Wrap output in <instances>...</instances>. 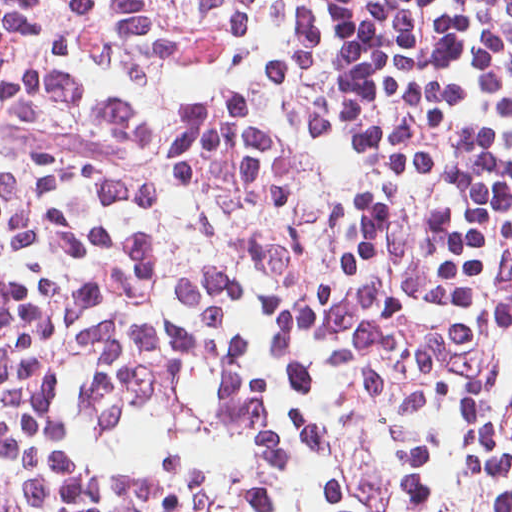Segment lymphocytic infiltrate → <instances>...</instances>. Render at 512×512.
Here are the masks:
<instances>
[{"label":"lymphocytic infiltrate","instance_id":"1","mask_svg":"<svg viewBox=\"0 0 512 512\" xmlns=\"http://www.w3.org/2000/svg\"><path fill=\"white\" fill-rule=\"evenodd\" d=\"M0 512H512V0H0Z\"/></svg>","mask_w":512,"mask_h":512}]
</instances>
